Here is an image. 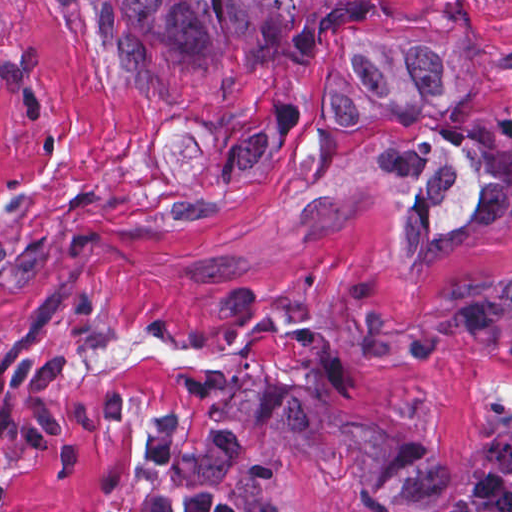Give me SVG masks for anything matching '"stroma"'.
Wrapping results in <instances>:
<instances>
[{
	"instance_id": "1",
	"label": "stroma",
	"mask_w": 512,
	"mask_h": 512,
	"mask_svg": "<svg viewBox=\"0 0 512 512\" xmlns=\"http://www.w3.org/2000/svg\"><path fill=\"white\" fill-rule=\"evenodd\" d=\"M362 1L469 30L476 97L333 112L330 37L195 55L123 0H0V512H512V344L380 334L512 270V217L426 267L391 240L405 150L512 110V0Z\"/></svg>"
}]
</instances>
